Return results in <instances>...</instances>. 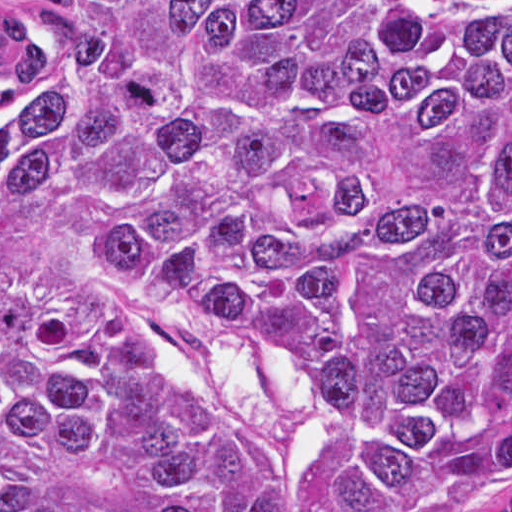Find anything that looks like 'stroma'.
<instances>
[{
	"label": "stroma",
	"mask_w": 512,
	"mask_h": 512,
	"mask_svg": "<svg viewBox=\"0 0 512 512\" xmlns=\"http://www.w3.org/2000/svg\"><path fill=\"white\" fill-rule=\"evenodd\" d=\"M0 289L77 313H129L150 346L174 359L198 390L273 444L288 467L293 512H315L310 487L326 450L369 434L316 386L267 363L238 331L190 323L94 287L0 280Z\"/></svg>",
	"instance_id": "stroma-1"
}]
</instances>
